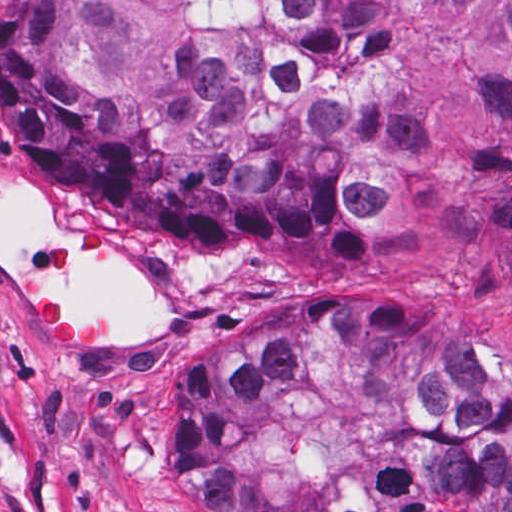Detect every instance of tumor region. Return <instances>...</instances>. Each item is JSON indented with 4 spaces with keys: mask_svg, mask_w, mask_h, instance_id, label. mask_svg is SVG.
<instances>
[{
    "mask_svg": "<svg viewBox=\"0 0 512 512\" xmlns=\"http://www.w3.org/2000/svg\"><path fill=\"white\" fill-rule=\"evenodd\" d=\"M459 2L1 0V121L51 190L179 262L261 278L430 201L427 135L369 101L410 4L453 19ZM449 93L478 161L459 220L512 242V0ZM58 233L52 204L1 170V266L31 272V243ZM51 280L119 332L163 325L127 258ZM30 315L51 351L98 341L55 298ZM428 511L512 512V381L461 345L352 301L203 381L183 512Z\"/></svg>",
    "mask_w": 512,
    "mask_h": 512,
    "instance_id": "1",
    "label": "tumor region"
}]
</instances>
